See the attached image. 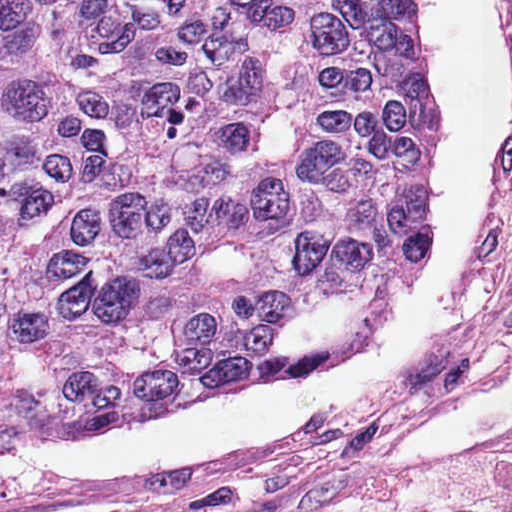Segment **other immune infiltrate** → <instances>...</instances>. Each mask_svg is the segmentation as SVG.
I'll return each mask as SVG.
<instances>
[{
  "mask_svg": "<svg viewBox=\"0 0 512 512\" xmlns=\"http://www.w3.org/2000/svg\"><path fill=\"white\" fill-rule=\"evenodd\" d=\"M512 502V447L464 469L397 488L355 512H468Z\"/></svg>",
  "mask_w": 512,
  "mask_h": 512,
  "instance_id": "bc1004c8",
  "label": "other immune infiltrate"
}]
</instances>
